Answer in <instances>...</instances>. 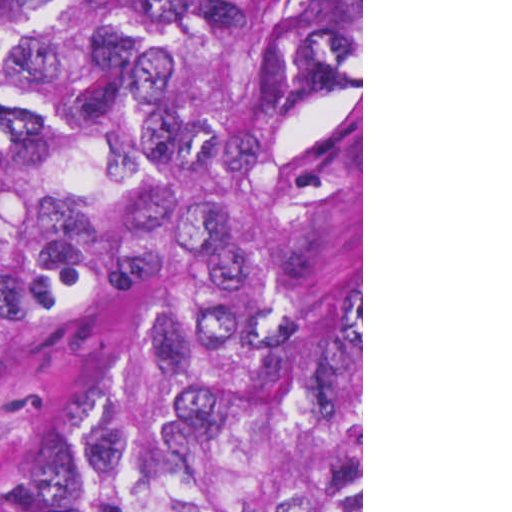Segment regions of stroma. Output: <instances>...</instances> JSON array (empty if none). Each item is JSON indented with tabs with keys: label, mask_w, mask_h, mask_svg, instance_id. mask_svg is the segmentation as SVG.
Here are the masks:
<instances>
[{
	"label": "stroma",
	"mask_w": 512,
	"mask_h": 512,
	"mask_svg": "<svg viewBox=\"0 0 512 512\" xmlns=\"http://www.w3.org/2000/svg\"><path fill=\"white\" fill-rule=\"evenodd\" d=\"M360 180L363 512V0L361 87L302 93L283 152L226 180L162 132L158 191L215 219L209 249L149 273L113 311L50 333L0 361V512H77L68 426L146 297L177 274L262 246Z\"/></svg>",
	"instance_id": "stroma-1"
}]
</instances>
